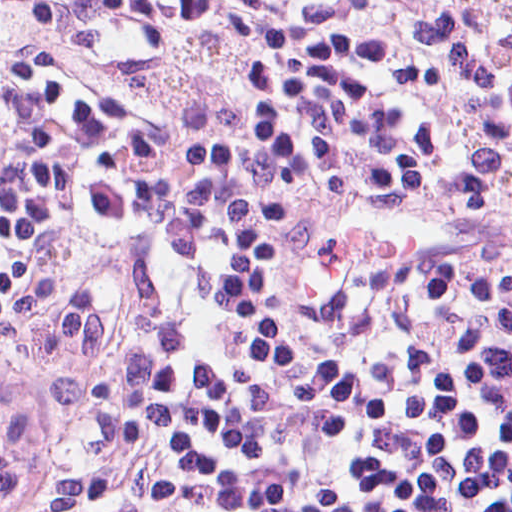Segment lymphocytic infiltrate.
Returning a JSON list of instances; mask_svg holds the SVG:
<instances>
[{
    "mask_svg": "<svg viewBox=\"0 0 512 512\" xmlns=\"http://www.w3.org/2000/svg\"><path fill=\"white\" fill-rule=\"evenodd\" d=\"M49 8L0 59V512H512V1Z\"/></svg>",
    "mask_w": 512,
    "mask_h": 512,
    "instance_id": "f902f5d3",
    "label": "lymphocytic infiltrate"
}]
</instances>
